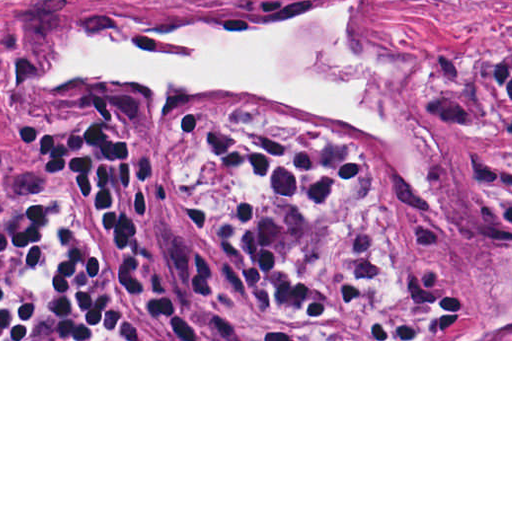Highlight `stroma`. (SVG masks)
Wrapping results in <instances>:
<instances>
[{
    "mask_svg": "<svg viewBox=\"0 0 512 512\" xmlns=\"http://www.w3.org/2000/svg\"><path fill=\"white\" fill-rule=\"evenodd\" d=\"M340 0H0V221L35 196L75 262L106 280L170 339L0 341H512V0H379L338 19L344 51L371 63L389 91L397 148L331 128L285 105L231 94L151 101L119 76L34 84L38 66L86 35L136 48L179 25L244 29L304 17ZM239 130L323 134L367 173L299 234L298 268L329 276L362 236L373 289L356 313L307 324L308 339H185L178 317L133 269L118 236L78 195L48 189L54 170L32 153L48 121L109 119L153 150L139 171L147 220L138 261L158 294L182 301L193 261L208 268V315L273 331L275 304L185 211L222 197H261L266 181L201 158L182 116ZM410 302L405 339H375Z\"/></svg>",
    "mask_w": 512,
    "mask_h": 512,
    "instance_id": "35a3bbf8",
    "label": "stroma"
}]
</instances>
